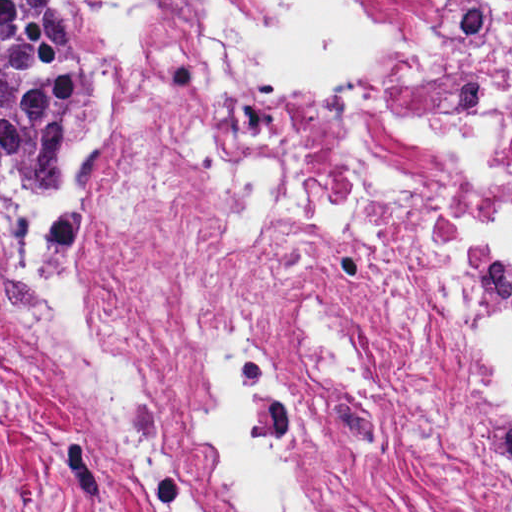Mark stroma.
Here are the masks:
<instances>
[{
    "label": "stroma",
    "mask_w": 512,
    "mask_h": 512,
    "mask_svg": "<svg viewBox=\"0 0 512 512\" xmlns=\"http://www.w3.org/2000/svg\"><path fill=\"white\" fill-rule=\"evenodd\" d=\"M76 25L95 46V111L75 167V207L58 210L34 195L0 127V196L43 233L90 230L96 216V164L123 124L157 146L191 189L206 217L234 247L248 249L281 230L317 233L356 261L411 308L435 350L482 379L461 341L392 275L379 270L295 204L281 202L248 240L232 232L192 159L160 138L121 93L116 57L87 15V0H69ZM511 410L512 402L503 401ZM0 512H143L72 397L0 328Z\"/></svg>",
    "instance_id": "obj_1"
}]
</instances>
